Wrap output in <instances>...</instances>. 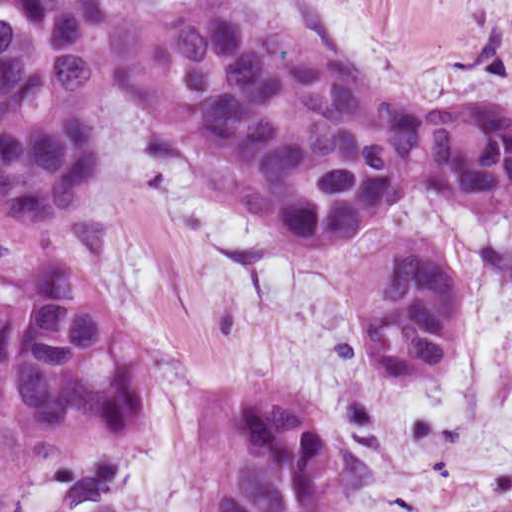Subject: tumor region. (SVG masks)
<instances>
[{
    "instance_id": "tumor-region-1",
    "label": "tumor region",
    "mask_w": 512,
    "mask_h": 512,
    "mask_svg": "<svg viewBox=\"0 0 512 512\" xmlns=\"http://www.w3.org/2000/svg\"><path fill=\"white\" fill-rule=\"evenodd\" d=\"M163 104L196 161L299 243L355 237L401 196L512 219V104L434 106L242 0L139 11L120 0H0V223H56L99 174L115 88ZM396 237L357 275L383 383L454 364L472 277ZM137 325L80 265L0 269V512H368L345 422L299 387L232 383L191 403L184 457L146 436ZM512 512V454L485 508Z\"/></svg>"
}]
</instances>
